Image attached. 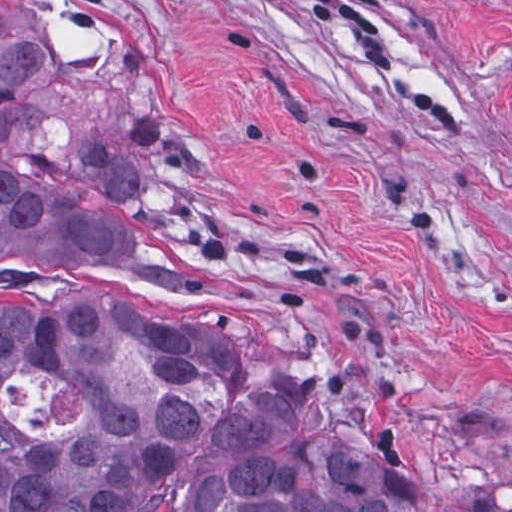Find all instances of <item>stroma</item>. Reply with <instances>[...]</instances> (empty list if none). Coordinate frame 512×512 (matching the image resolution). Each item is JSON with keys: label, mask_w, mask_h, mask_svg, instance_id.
Listing matches in <instances>:
<instances>
[{"label": "stroma", "mask_w": 512, "mask_h": 512, "mask_svg": "<svg viewBox=\"0 0 512 512\" xmlns=\"http://www.w3.org/2000/svg\"><path fill=\"white\" fill-rule=\"evenodd\" d=\"M42 43L11 153L230 270L32 298L218 331L289 437L419 512H512V0H0Z\"/></svg>", "instance_id": "35a3bbf8"}]
</instances>
